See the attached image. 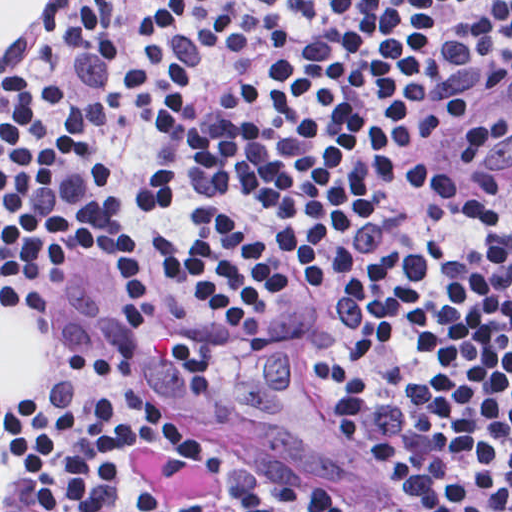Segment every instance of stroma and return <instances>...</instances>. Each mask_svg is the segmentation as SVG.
Segmentation results:
<instances>
[{
  "label": "stroma",
  "mask_w": 512,
  "mask_h": 512,
  "mask_svg": "<svg viewBox=\"0 0 512 512\" xmlns=\"http://www.w3.org/2000/svg\"><path fill=\"white\" fill-rule=\"evenodd\" d=\"M0 1H49L42 18L18 44L0 46V76L34 61L65 13L86 21L103 38L116 64L121 122L137 185L141 137L133 96L120 79V9L112 1L512 0ZM493 107L447 139L434 158L447 176L495 195L508 184H480L463 171L468 141ZM162 225L141 218L137 209L140 310L130 324L113 312V292L102 277H81L46 301H5L25 307L47 329V377L23 401H0V419L40 397L62 379L74 358L95 347L143 385L165 411L144 421L137 437V463L149 483L195 512H235L229 470L249 465H325L346 479L388 491L381 465L323 391L311 342L308 295L252 340L232 345L202 340L145 284V261L159 245ZM0 512H21L1 477ZM69 512L141 511L130 499L108 491Z\"/></svg>",
  "instance_id": "35a3bbf8"
}]
</instances>
